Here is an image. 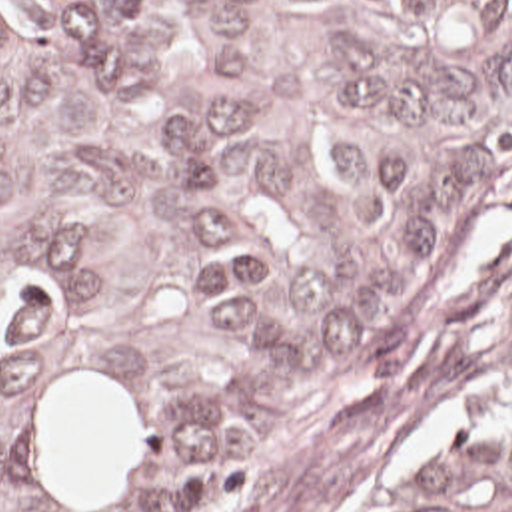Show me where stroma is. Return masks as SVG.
<instances>
[{
	"label": "stroma",
	"instance_id": "stroma-1",
	"mask_svg": "<svg viewBox=\"0 0 512 512\" xmlns=\"http://www.w3.org/2000/svg\"><path fill=\"white\" fill-rule=\"evenodd\" d=\"M512 385V177L431 241L253 512H357Z\"/></svg>",
	"mask_w": 512,
	"mask_h": 512
}]
</instances>
